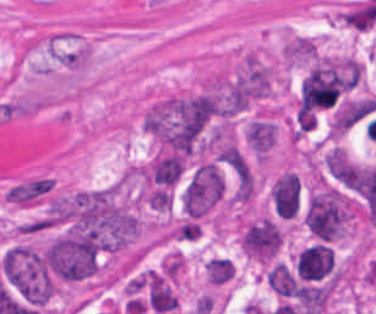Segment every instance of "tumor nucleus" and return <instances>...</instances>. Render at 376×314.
<instances>
[{
    "mask_svg": "<svg viewBox=\"0 0 376 314\" xmlns=\"http://www.w3.org/2000/svg\"><path fill=\"white\" fill-rule=\"evenodd\" d=\"M333 265V248L313 243L300 252L296 260V273L300 280H319L330 273Z\"/></svg>",
    "mask_w": 376,
    "mask_h": 314,
    "instance_id": "2cbd58db",
    "label": "tumor nucleus"
},
{
    "mask_svg": "<svg viewBox=\"0 0 376 314\" xmlns=\"http://www.w3.org/2000/svg\"><path fill=\"white\" fill-rule=\"evenodd\" d=\"M375 109V96L349 100L334 114L333 126L337 131L350 129Z\"/></svg>",
    "mask_w": 376,
    "mask_h": 314,
    "instance_id": "8087334f",
    "label": "tumor nucleus"
},
{
    "mask_svg": "<svg viewBox=\"0 0 376 314\" xmlns=\"http://www.w3.org/2000/svg\"><path fill=\"white\" fill-rule=\"evenodd\" d=\"M183 169L182 156L172 152H159L143 171V175L151 187L169 189L179 181Z\"/></svg>",
    "mask_w": 376,
    "mask_h": 314,
    "instance_id": "3d1891a8",
    "label": "tumor nucleus"
},
{
    "mask_svg": "<svg viewBox=\"0 0 376 314\" xmlns=\"http://www.w3.org/2000/svg\"><path fill=\"white\" fill-rule=\"evenodd\" d=\"M285 59L290 61H313L317 51L308 38L296 37L284 47Z\"/></svg>",
    "mask_w": 376,
    "mask_h": 314,
    "instance_id": "f7901128",
    "label": "tumor nucleus"
},
{
    "mask_svg": "<svg viewBox=\"0 0 376 314\" xmlns=\"http://www.w3.org/2000/svg\"><path fill=\"white\" fill-rule=\"evenodd\" d=\"M328 171L341 183L350 187L355 165L341 146H334L325 156Z\"/></svg>",
    "mask_w": 376,
    "mask_h": 314,
    "instance_id": "feef74b5",
    "label": "tumor nucleus"
},
{
    "mask_svg": "<svg viewBox=\"0 0 376 314\" xmlns=\"http://www.w3.org/2000/svg\"><path fill=\"white\" fill-rule=\"evenodd\" d=\"M5 284L24 303L43 307L54 295V275L41 248L10 244L0 258Z\"/></svg>",
    "mask_w": 376,
    "mask_h": 314,
    "instance_id": "2f306a5c",
    "label": "tumor nucleus"
},
{
    "mask_svg": "<svg viewBox=\"0 0 376 314\" xmlns=\"http://www.w3.org/2000/svg\"><path fill=\"white\" fill-rule=\"evenodd\" d=\"M352 207L344 193L334 187L316 190L308 200L305 222L312 236L334 242L348 232Z\"/></svg>",
    "mask_w": 376,
    "mask_h": 314,
    "instance_id": "8643909e",
    "label": "tumor nucleus"
},
{
    "mask_svg": "<svg viewBox=\"0 0 376 314\" xmlns=\"http://www.w3.org/2000/svg\"><path fill=\"white\" fill-rule=\"evenodd\" d=\"M225 192L215 163L204 162L194 171L184 193L186 211L191 218H200Z\"/></svg>",
    "mask_w": 376,
    "mask_h": 314,
    "instance_id": "5ab6c2c4",
    "label": "tumor nucleus"
},
{
    "mask_svg": "<svg viewBox=\"0 0 376 314\" xmlns=\"http://www.w3.org/2000/svg\"><path fill=\"white\" fill-rule=\"evenodd\" d=\"M270 196L278 214L294 217L300 203V177L296 173L284 172L275 179Z\"/></svg>",
    "mask_w": 376,
    "mask_h": 314,
    "instance_id": "2083b535",
    "label": "tumor nucleus"
},
{
    "mask_svg": "<svg viewBox=\"0 0 376 314\" xmlns=\"http://www.w3.org/2000/svg\"><path fill=\"white\" fill-rule=\"evenodd\" d=\"M249 145L262 156L275 142L276 124L259 119H252L246 129Z\"/></svg>",
    "mask_w": 376,
    "mask_h": 314,
    "instance_id": "c2bd9aea",
    "label": "tumor nucleus"
},
{
    "mask_svg": "<svg viewBox=\"0 0 376 314\" xmlns=\"http://www.w3.org/2000/svg\"><path fill=\"white\" fill-rule=\"evenodd\" d=\"M268 282L271 289L279 296L291 297L297 293V283L295 277L289 269L280 264H274L267 273Z\"/></svg>",
    "mask_w": 376,
    "mask_h": 314,
    "instance_id": "3e47fb67",
    "label": "tumor nucleus"
}]
</instances>
